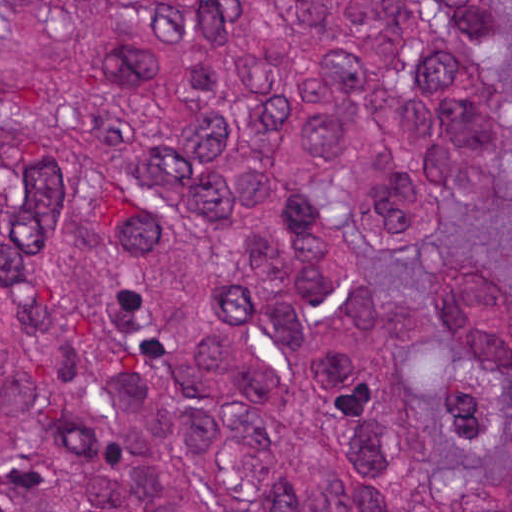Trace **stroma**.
<instances>
[{
	"label": "stroma",
	"mask_w": 512,
	"mask_h": 512,
	"mask_svg": "<svg viewBox=\"0 0 512 512\" xmlns=\"http://www.w3.org/2000/svg\"><path fill=\"white\" fill-rule=\"evenodd\" d=\"M1 1H512V0H0V512H1ZM461 254L498 260L512 279V204L468 215L437 242L434 259Z\"/></svg>",
	"instance_id": "obj_1"
}]
</instances>
